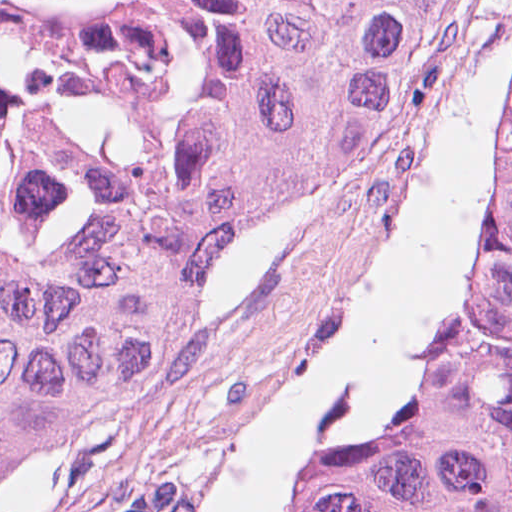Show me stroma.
<instances>
[{
  "mask_svg": "<svg viewBox=\"0 0 512 512\" xmlns=\"http://www.w3.org/2000/svg\"><path fill=\"white\" fill-rule=\"evenodd\" d=\"M507 64L480 259L505 188L512 0H450L302 220L205 286L206 309L178 349L133 396L33 456L0 512H203L239 422L349 289L463 91ZM414 404L381 447L401 442Z\"/></svg>",
  "mask_w": 512,
  "mask_h": 512,
  "instance_id": "stroma-1",
  "label": "stroma"
}]
</instances>
